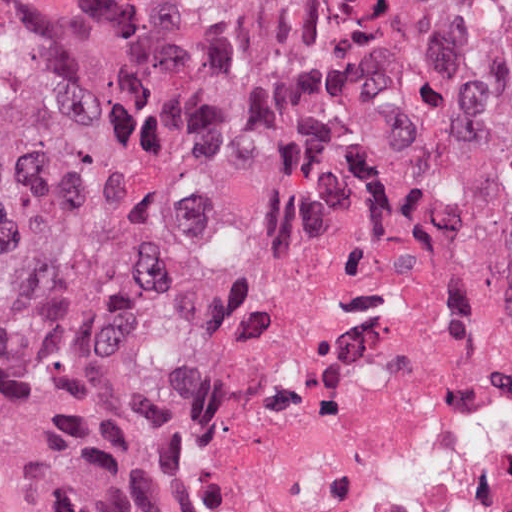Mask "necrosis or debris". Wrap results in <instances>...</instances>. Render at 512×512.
<instances>
[{"label":"necrosis or debris","instance_id":"obj_1","mask_svg":"<svg viewBox=\"0 0 512 512\" xmlns=\"http://www.w3.org/2000/svg\"><path fill=\"white\" fill-rule=\"evenodd\" d=\"M153 374L197 512H512V323L421 211L269 226L162 328Z\"/></svg>","mask_w":512,"mask_h":512}]
</instances>
